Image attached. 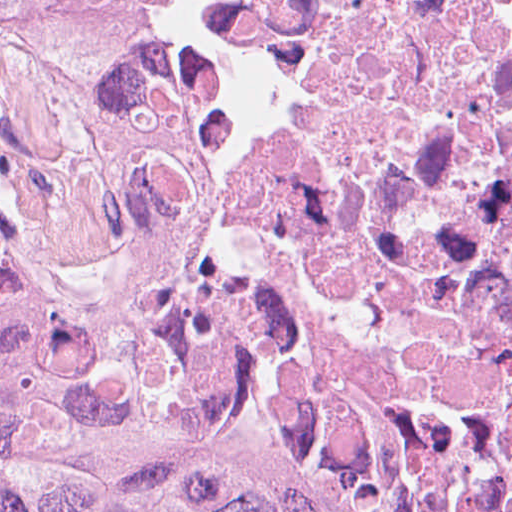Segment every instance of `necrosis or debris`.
I'll list each match as a JSON object with an SVG mask.
<instances>
[{
  "instance_id": "obj_1",
  "label": "necrosis or debris",
  "mask_w": 512,
  "mask_h": 512,
  "mask_svg": "<svg viewBox=\"0 0 512 512\" xmlns=\"http://www.w3.org/2000/svg\"><path fill=\"white\" fill-rule=\"evenodd\" d=\"M0 230L282 430L512 477V0H0Z\"/></svg>"
}]
</instances>
